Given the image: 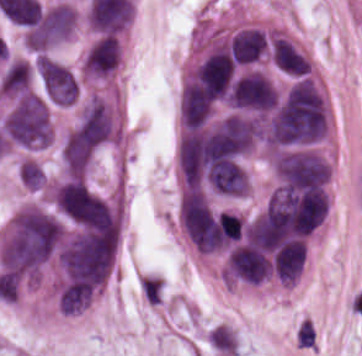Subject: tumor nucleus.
I'll use <instances>...</instances> for the list:
<instances>
[{"mask_svg":"<svg viewBox=\"0 0 362 356\" xmlns=\"http://www.w3.org/2000/svg\"><path fill=\"white\" fill-rule=\"evenodd\" d=\"M75 20L70 5L58 1L35 12L25 31L30 47H47L69 37Z\"/></svg>","mask_w":362,"mask_h":356,"instance_id":"2","label":"tumor nucleus"},{"mask_svg":"<svg viewBox=\"0 0 362 356\" xmlns=\"http://www.w3.org/2000/svg\"><path fill=\"white\" fill-rule=\"evenodd\" d=\"M7 138L20 146H46L52 138L50 110L42 94L20 93L0 119Z\"/></svg>","mask_w":362,"mask_h":356,"instance_id":"1","label":"tumor nucleus"},{"mask_svg":"<svg viewBox=\"0 0 362 356\" xmlns=\"http://www.w3.org/2000/svg\"><path fill=\"white\" fill-rule=\"evenodd\" d=\"M270 59L278 71L291 78L311 71L308 58L284 37H276L271 43Z\"/></svg>","mask_w":362,"mask_h":356,"instance_id":"6","label":"tumor nucleus"},{"mask_svg":"<svg viewBox=\"0 0 362 356\" xmlns=\"http://www.w3.org/2000/svg\"><path fill=\"white\" fill-rule=\"evenodd\" d=\"M205 339L211 350L220 356H233L237 353V338L231 327L216 324L207 330Z\"/></svg>","mask_w":362,"mask_h":356,"instance_id":"7","label":"tumor nucleus"},{"mask_svg":"<svg viewBox=\"0 0 362 356\" xmlns=\"http://www.w3.org/2000/svg\"><path fill=\"white\" fill-rule=\"evenodd\" d=\"M121 60L118 37L99 35L90 45L83 64L84 78L106 82L112 77Z\"/></svg>","mask_w":362,"mask_h":356,"instance_id":"4","label":"tumor nucleus"},{"mask_svg":"<svg viewBox=\"0 0 362 356\" xmlns=\"http://www.w3.org/2000/svg\"><path fill=\"white\" fill-rule=\"evenodd\" d=\"M276 88L261 71H248L237 77L227 90V101L238 109L266 111Z\"/></svg>","mask_w":362,"mask_h":356,"instance_id":"3","label":"tumor nucleus"},{"mask_svg":"<svg viewBox=\"0 0 362 356\" xmlns=\"http://www.w3.org/2000/svg\"><path fill=\"white\" fill-rule=\"evenodd\" d=\"M36 65L48 97L62 104L73 103L78 95V82L74 75L44 56H37Z\"/></svg>","mask_w":362,"mask_h":356,"instance_id":"5","label":"tumor nucleus"}]
</instances>
